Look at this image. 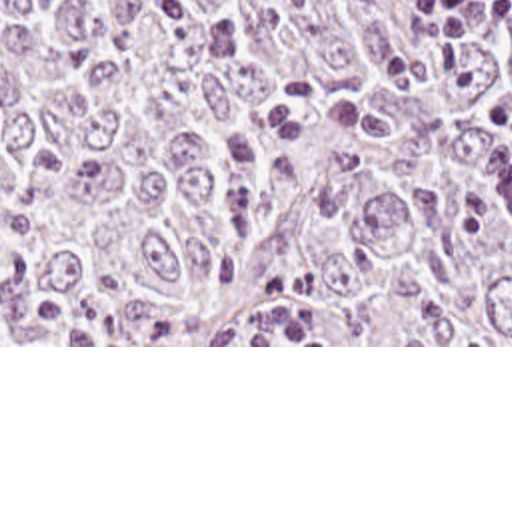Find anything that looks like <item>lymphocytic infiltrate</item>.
I'll return each instance as SVG.
<instances>
[{
	"instance_id": "1",
	"label": "lymphocytic infiltrate",
	"mask_w": 512,
	"mask_h": 512,
	"mask_svg": "<svg viewBox=\"0 0 512 512\" xmlns=\"http://www.w3.org/2000/svg\"><path fill=\"white\" fill-rule=\"evenodd\" d=\"M418 24L428 32L424 44L382 57L370 69L384 91L436 83L454 75L466 61L477 32L511 24V0H412ZM483 123L505 135L512 151V91L481 107Z\"/></svg>"
}]
</instances>
